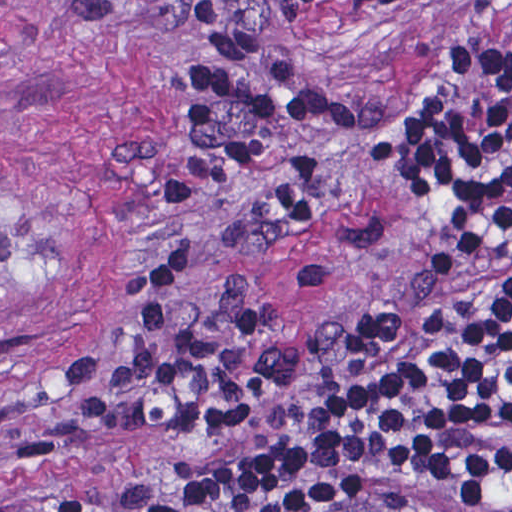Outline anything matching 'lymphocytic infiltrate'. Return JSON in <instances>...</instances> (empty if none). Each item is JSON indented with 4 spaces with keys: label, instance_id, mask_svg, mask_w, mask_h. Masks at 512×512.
<instances>
[{
    "label": "lymphocytic infiltrate",
    "instance_id": "obj_1",
    "mask_svg": "<svg viewBox=\"0 0 512 512\" xmlns=\"http://www.w3.org/2000/svg\"><path fill=\"white\" fill-rule=\"evenodd\" d=\"M429 93L396 115L254 49L180 59L177 177L239 224L352 233L371 328L285 348L197 248H143L71 383L76 410L174 436L170 459L71 512H512V66L470 52Z\"/></svg>",
    "mask_w": 512,
    "mask_h": 512
}]
</instances>
